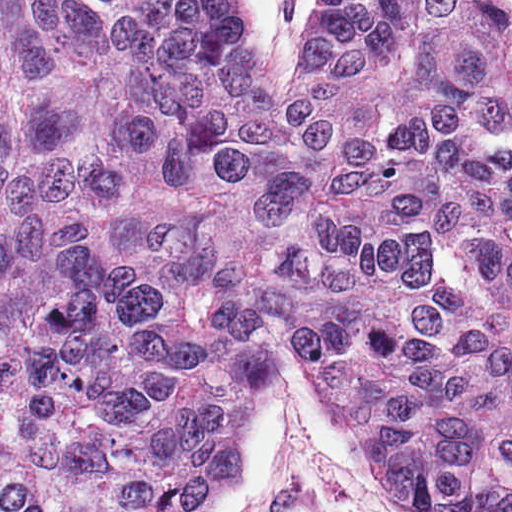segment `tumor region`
Instances as JSON below:
<instances>
[{"mask_svg":"<svg viewBox=\"0 0 512 512\" xmlns=\"http://www.w3.org/2000/svg\"><path fill=\"white\" fill-rule=\"evenodd\" d=\"M391 512H512V6L0 0V512H202L282 346Z\"/></svg>","mask_w":512,"mask_h":512,"instance_id":"e687c5a6","label":"tumor region"}]
</instances>
